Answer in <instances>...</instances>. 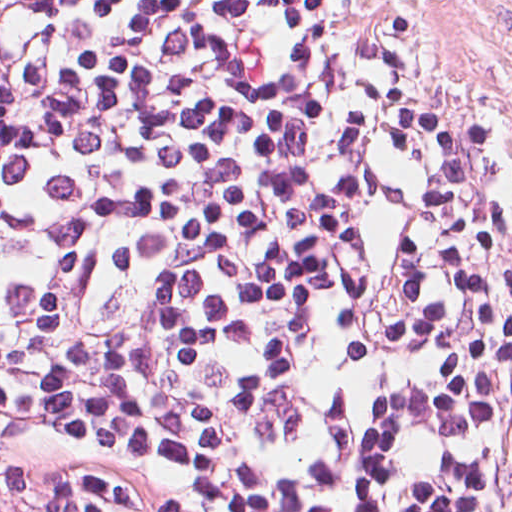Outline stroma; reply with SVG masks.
I'll use <instances>...</instances> for the list:
<instances>
[{"mask_svg":"<svg viewBox=\"0 0 512 512\" xmlns=\"http://www.w3.org/2000/svg\"><path fill=\"white\" fill-rule=\"evenodd\" d=\"M479 254L512 304V0H390Z\"/></svg>","mask_w":512,"mask_h":512,"instance_id":"35a3bbf8","label":"stroma"}]
</instances>
